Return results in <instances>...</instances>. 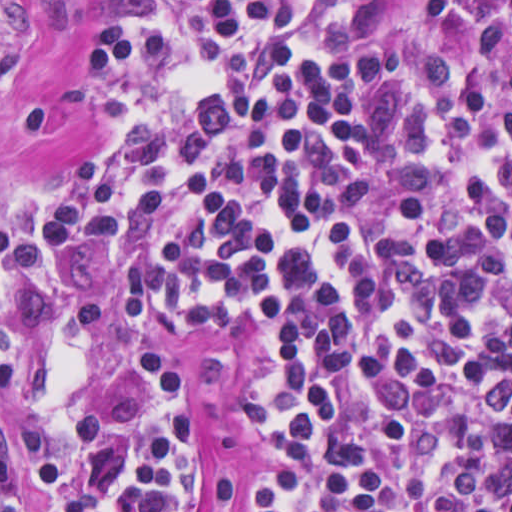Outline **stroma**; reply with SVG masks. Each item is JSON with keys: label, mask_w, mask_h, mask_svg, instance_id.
I'll use <instances>...</instances> for the list:
<instances>
[{"label": "stroma", "mask_w": 512, "mask_h": 512, "mask_svg": "<svg viewBox=\"0 0 512 512\" xmlns=\"http://www.w3.org/2000/svg\"><path fill=\"white\" fill-rule=\"evenodd\" d=\"M0 49L12 61L0 74V187L6 191V238L42 279L101 302L97 394L126 360L166 361L187 393L200 431L199 464L186 512H239L226 491L253 479L257 446L250 407L264 366L260 334L177 338L153 301L106 271L55 256L40 240L29 187L38 174L89 155L123 135L120 121H88L63 134L23 124L31 106L59 97L87 74L93 1H512V0H0ZM0 428L15 450L27 512H39L18 436L0 405Z\"/></svg>", "instance_id": "35a3bbf8"}]
</instances>
